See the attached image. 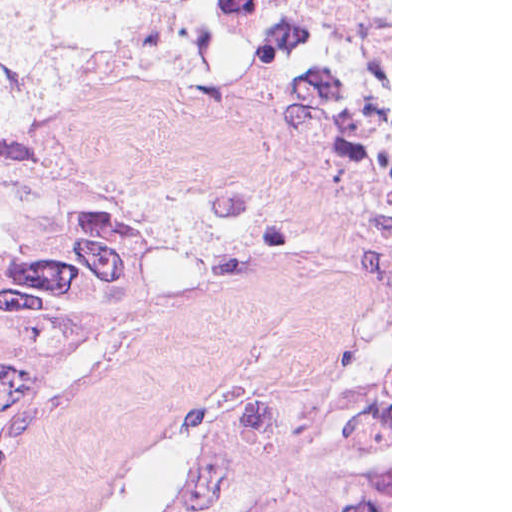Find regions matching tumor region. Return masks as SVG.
<instances>
[{
    "mask_svg": "<svg viewBox=\"0 0 512 512\" xmlns=\"http://www.w3.org/2000/svg\"><path fill=\"white\" fill-rule=\"evenodd\" d=\"M0 512H82L16 487V453L66 363L160 288L170 202L145 190L48 108L0 110ZM229 423L200 455L177 512H240L225 498ZM390 512V440L317 456L292 506Z\"/></svg>",
    "mask_w": 512,
    "mask_h": 512,
    "instance_id": "1",
    "label": "tumor region"
}]
</instances>
